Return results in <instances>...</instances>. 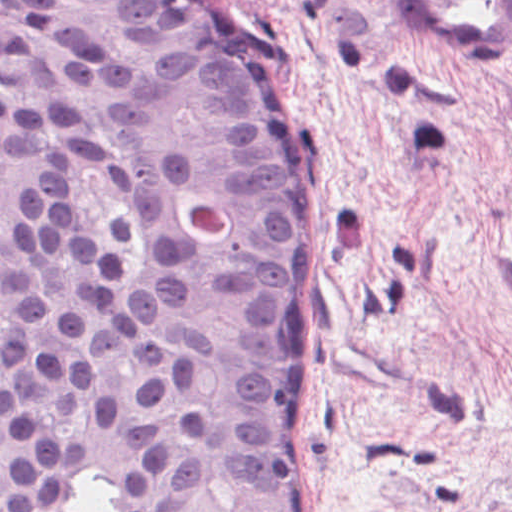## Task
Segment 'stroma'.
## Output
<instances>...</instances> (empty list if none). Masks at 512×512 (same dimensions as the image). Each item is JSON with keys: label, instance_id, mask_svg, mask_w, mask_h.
<instances>
[{"label": "stroma", "instance_id": "stroma-1", "mask_svg": "<svg viewBox=\"0 0 512 512\" xmlns=\"http://www.w3.org/2000/svg\"><path fill=\"white\" fill-rule=\"evenodd\" d=\"M307 123L312 512H512V55L417 61L398 0H201Z\"/></svg>", "mask_w": 512, "mask_h": 512}]
</instances>
